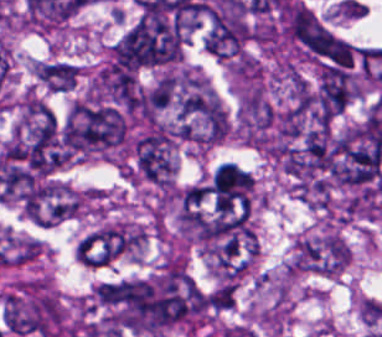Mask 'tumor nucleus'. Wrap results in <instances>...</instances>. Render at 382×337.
I'll return each instance as SVG.
<instances>
[{"label": "tumor nucleus", "mask_w": 382, "mask_h": 337, "mask_svg": "<svg viewBox=\"0 0 382 337\" xmlns=\"http://www.w3.org/2000/svg\"><path fill=\"white\" fill-rule=\"evenodd\" d=\"M347 263V247L336 234L299 240L292 272L337 276Z\"/></svg>", "instance_id": "2083b535"}, {"label": "tumor nucleus", "mask_w": 382, "mask_h": 337, "mask_svg": "<svg viewBox=\"0 0 382 337\" xmlns=\"http://www.w3.org/2000/svg\"><path fill=\"white\" fill-rule=\"evenodd\" d=\"M275 117L276 108L266 97L246 93L241 113V129L249 140L265 145L271 136Z\"/></svg>", "instance_id": "8087334f"}, {"label": "tumor nucleus", "mask_w": 382, "mask_h": 337, "mask_svg": "<svg viewBox=\"0 0 382 337\" xmlns=\"http://www.w3.org/2000/svg\"><path fill=\"white\" fill-rule=\"evenodd\" d=\"M126 121L117 108L82 100L72 102L62 130L61 142L72 150H88L123 139Z\"/></svg>", "instance_id": "5ab6c2c4"}, {"label": "tumor nucleus", "mask_w": 382, "mask_h": 337, "mask_svg": "<svg viewBox=\"0 0 382 337\" xmlns=\"http://www.w3.org/2000/svg\"><path fill=\"white\" fill-rule=\"evenodd\" d=\"M143 232L138 227L112 224L87 234L82 242V266L105 267L140 249Z\"/></svg>", "instance_id": "3d1891a8"}, {"label": "tumor nucleus", "mask_w": 382, "mask_h": 337, "mask_svg": "<svg viewBox=\"0 0 382 337\" xmlns=\"http://www.w3.org/2000/svg\"><path fill=\"white\" fill-rule=\"evenodd\" d=\"M78 66L67 61H41L36 63V79L51 91H71L77 82Z\"/></svg>", "instance_id": "c2bd9aea"}, {"label": "tumor nucleus", "mask_w": 382, "mask_h": 337, "mask_svg": "<svg viewBox=\"0 0 382 337\" xmlns=\"http://www.w3.org/2000/svg\"><path fill=\"white\" fill-rule=\"evenodd\" d=\"M118 322L136 333L190 328L200 291L187 271L171 267L123 278L116 289Z\"/></svg>", "instance_id": "2f306a5c"}, {"label": "tumor nucleus", "mask_w": 382, "mask_h": 337, "mask_svg": "<svg viewBox=\"0 0 382 337\" xmlns=\"http://www.w3.org/2000/svg\"><path fill=\"white\" fill-rule=\"evenodd\" d=\"M137 172L156 185H170L175 168V137L167 124L153 123L131 144Z\"/></svg>", "instance_id": "2cbd58db"}, {"label": "tumor nucleus", "mask_w": 382, "mask_h": 337, "mask_svg": "<svg viewBox=\"0 0 382 337\" xmlns=\"http://www.w3.org/2000/svg\"><path fill=\"white\" fill-rule=\"evenodd\" d=\"M184 31L157 16L145 15L110 49L112 68L153 66L174 61Z\"/></svg>", "instance_id": "8643909e"}]
</instances>
